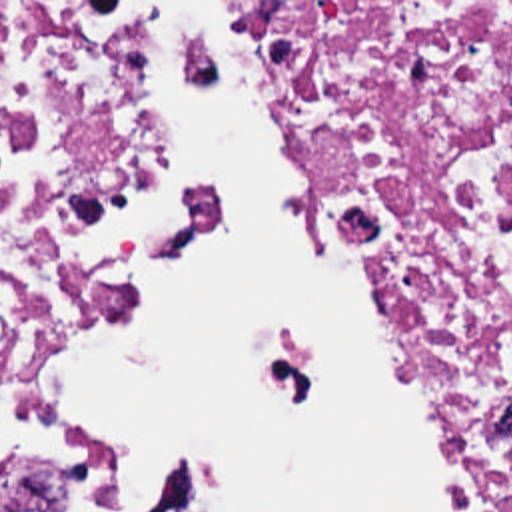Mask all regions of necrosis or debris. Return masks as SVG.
Returning <instances> with one entry per match:
<instances>
[{"label": "necrosis or debris", "mask_w": 512, "mask_h": 512, "mask_svg": "<svg viewBox=\"0 0 512 512\" xmlns=\"http://www.w3.org/2000/svg\"><path fill=\"white\" fill-rule=\"evenodd\" d=\"M315 168L493 512H512V2H250ZM190 2H0V512L102 469L36 385L54 327L192 230L158 116Z\"/></svg>", "instance_id": "1"}]
</instances>
